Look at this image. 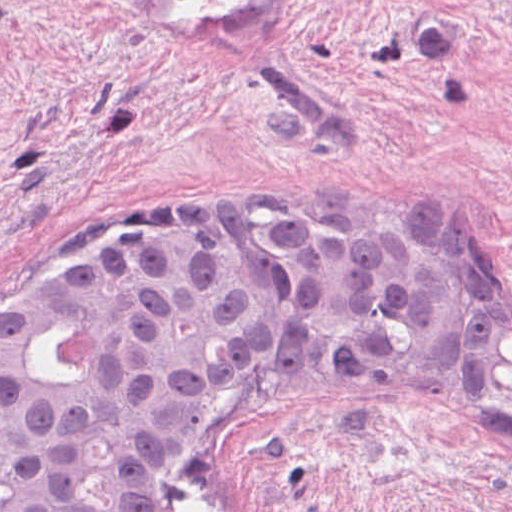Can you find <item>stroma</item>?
Instances as JSON below:
<instances>
[{
    "mask_svg": "<svg viewBox=\"0 0 512 512\" xmlns=\"http://www.w3.org/2000/svg\"><path fill=\"white\" fill-rule=\"evenodd\" d=\"M256 208L420 219L512 284V0H0V318ZM178 512H512V461L285 402L211 441Z\"/></svg>",
    "mask_w": 512,
    "mask_h": 512,
    "instance_id": "obj_1",
    "label": "stroma"
}]
</instances>
